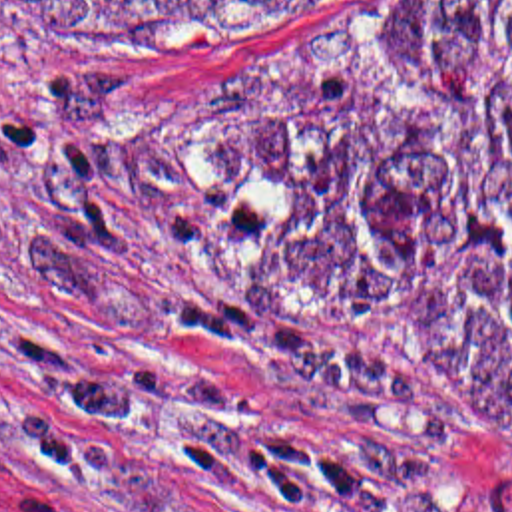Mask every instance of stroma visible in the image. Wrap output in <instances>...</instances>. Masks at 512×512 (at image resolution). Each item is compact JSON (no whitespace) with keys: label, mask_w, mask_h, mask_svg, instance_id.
<instances>
[{"label":"stroma","mask_w":512,"mask_h":512,"mask_svg":"<svg viewBox=\"0 0 512 512\" xmlns=\"http://www.w3.org/2000/svg\"><path fill=\"white\" fill-rule=\"evenodd\" d=\"M430 1L0 0V512H512L506 433L261 302Z\"/></svg>","instance_id":"35a3bbf8"}]
</instances>
